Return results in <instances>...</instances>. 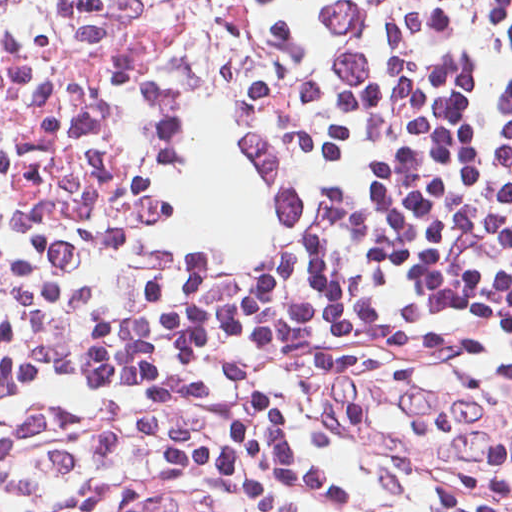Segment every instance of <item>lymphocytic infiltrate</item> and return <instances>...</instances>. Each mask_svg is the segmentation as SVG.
Returning <instances> with one entry per match:
<instances>
[{
  "instance_id": "1",
  "label": "lymphocytic infiltrate",
  "mask_w": 512,
  "mask_h": 512,
  "mask_svg": "<svg viewBox=\"0 0 512 512\" xmlns=\"http://www.w3.org/2000/svg\"><path fill=\"white\" fill-rule=\"evenodd\" d=\"M0 512H512V0H0Z\"/></svg>"
}]
</instances>
